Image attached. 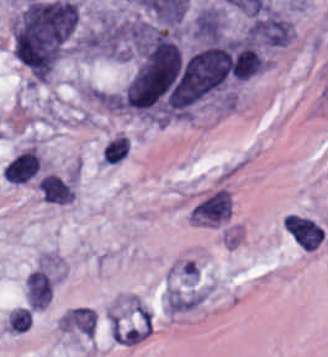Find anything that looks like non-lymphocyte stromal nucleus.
Instances as JSON below:
<instances>
[{
    "label": "non-lymphocyte stromal nucleus",
    "instance_id": "dd21d789",
    "mask_svg": "<svg viewBox=\"0 0 328 357\" xmlns=\"http://www.w3.org/2000/svg\"><path fill=\"white\" fill-rule=\"evenodd\" d=\"M213 291V282L194 257L182 256L167 268L163 308L170 316L189 313L202 305Z\"/></svg>",
    "mask_w": 328,
    "mask_h": 357
},
{
    "label": "non-lymphocyte stromal nucleus",
    "instance_id": "a72fc3eb",
    "mask_svg": "<svg viewBox=\"0 0 328 357\" xmlns=\"http://www.w3.org/2000/svg\"><path fill=\"white\" fill-rule=\"evenodd\" d=\"M106 328L116 346H136L149 337L152 315L145 308H110Z\"/></svg>",
    "mask_w": 328,
    "mask_h": 357
},
{
    "label": "non-lymphocyte stromal nucleus",
    "instance_id": "fc2b8d12",
    "mask_svg": "<svg viewBox=\"0 0 328 357\" xmlns=\"http://www.w3.org/2000/svg\"><path fill=\"white\" fill-rule=\"evenodd\" d=\"M231 196L226 189H218L195 205L189 219L200 225H218L230 214Z\"/></svg>",
    "mask_w": 328,
    "mask_h": 357
},
{
    "label": "non-lymphocyte stromal nucleus",
    "instance_id": "3746e769",
    "mask_svg": "<svg viewBox=\"0 0 328 357\" xmlns=\"http://www.w3.org/2000/svg\"><path fill=\"white\" fill-rule=\"evenodd\" d=\"M280 227L301 252H314L328 235L325 224L308 213L290 212L281 218Z\"/></svg>",
    "mask_w": 328,
    "mask_h": 357
},
{
    "label": "non-lymphocyte stromal nucleus",
    "instance_id": "81446118",
    "mask_svg": "<svg viewBox=\"0 0 328 357\" xmlns=\"http://www.w3.org/2000/svg\"><path fill=\"white\" fill-rule=\"evenodd\" d=\"M37 187L47 203L68 204L74 195V191L67 182L50 173L39 180Z\"/></svg>",
    "mask_w": 328,
    "mask_h": 357
}]
</instances>
